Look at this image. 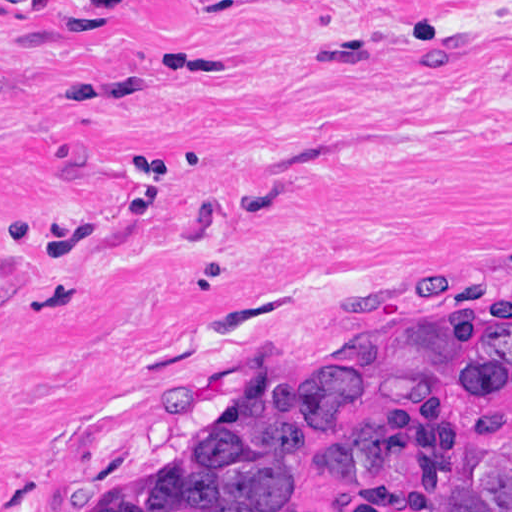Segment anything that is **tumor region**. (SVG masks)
Wrapping results in <instances>:
<instances>
[{
    "instance_id": "1",
    "label": "tumor region",
    "mask_w": 512,
    "mask_h": 512,
    "mask_svg": "<svg viewBox=\"0 0 512 512\" xmlns=\"http://www.w3.org/2000/svg\"><path fill=\"white\" fill-rule=\"evenodd\" d=\"M85 512H512V312L342 326Z\"/></svg>"
}]
</instances>
